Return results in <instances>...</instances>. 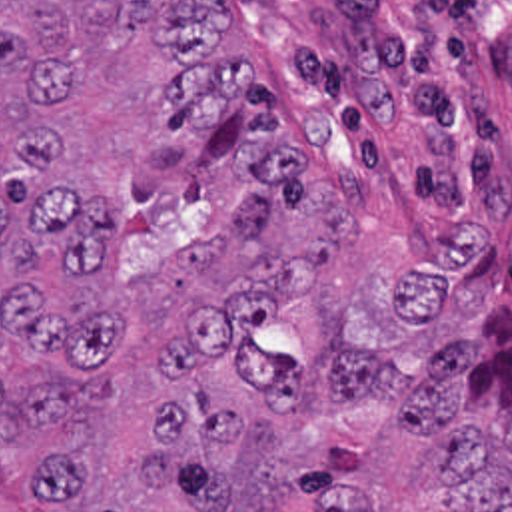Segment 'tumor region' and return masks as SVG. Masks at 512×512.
Segmentation results:
<instances>
[{
  "label": "tumor region",
  "instance_id": "tumor-region-1",
  "mask_svg": "<svg viewBox=\"0 0 512 512\" xmlns=\"http://www.w3.org/2000/svg\"><path fill=\"white\" fill-rule=\"evenodd\" d=\"M226 33L222 0H0V512H372L260 342L354 213ZM316 394L388 410L450 512H512V308L416 368L340 338Z\"/></svg>",
  "mask_w": 512,
  "mask_h": 512
}]
</instances>
